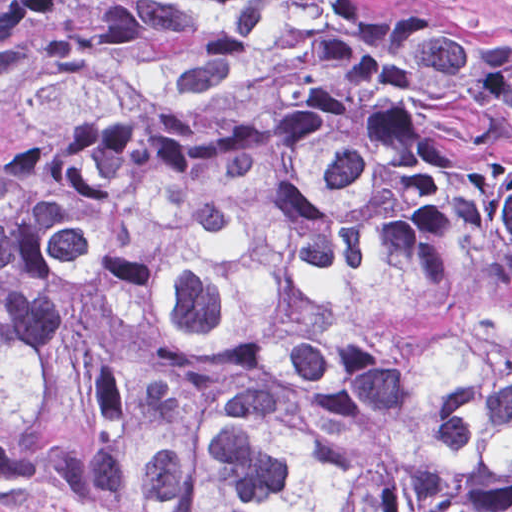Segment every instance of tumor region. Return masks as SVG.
Returning <instances> with one entry per match:
<instances>
[{"mask_svg":"<svg viewBox=\"0 0 512 512\" xmlns=\"http://www.w3.org/2000/svg\"><path fill=\"white\" fill-rule=\"evenodd\" d=\"M0 512H512V32L132 0L0 163Z\"/></svg>","mask_w":512,"mask_h":512,"instance_id":"tumor-region-1","label":"tumor region"}]
</instances>
